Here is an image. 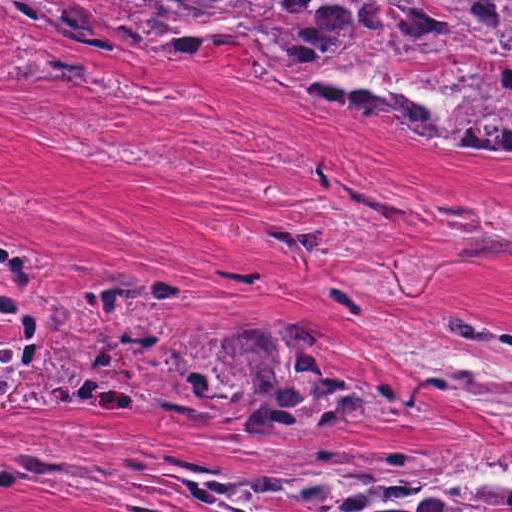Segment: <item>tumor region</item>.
Returning <instances> with one entry per match:
<instances>
[{"label": "tumor region", "mask_w": 512, "mask_h": 512, "mask_svg": "<svg viewBox=\"0 0 512 512\" xmlns=\"http://www.w3.org/2000/svg\"><path fill=\"white\" fill-rule=\"evenodd\" d=\"M22 10L107 58L186 65L242 46L336 110H389L430 149L512 148V0H0V31ZM51 270L36 250L0 249V406L199 417L236 396L203 343L141 316L183 297L179 287L105 267L42 292ZM231 341L247 423L331 429L424 406L331 363L329 335L294 315ZM400 351L439 398L493 431L497 458L393 455L276 475L171 453L157 472L207 499L319 494L280 499L309 512H512V318L452 303Z\"/></svg>", "instance_id": "obj_1"}]
</instances>
